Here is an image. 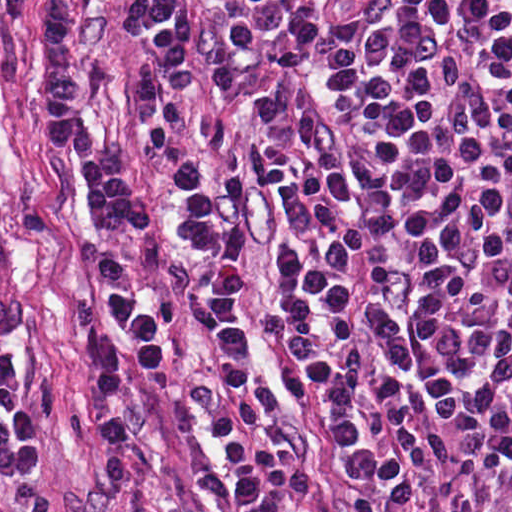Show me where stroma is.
<instances>
[{"label": "stroma", "instance_id": "obj_1", "mask_svg": "<svg viewBox=\"0 0 512 512\" xmlns=\"http://www.w3.org/2000/svg\"><path fill=\"white\" fill-rule=\"evenodd\" d=\"M69 1L85 44V127L127 161L158 210V229L144 234L124 220L91 233L68 156L35 124L40 0H0V394L39 435L26 473L0 478V512H235L209 390L206 325L189 291L193 260L173 234L172 190L138 133L134 64L164 80L193 141L242 177V123L266 76L249 43L253 20L227 0H195L200 89L180 99L136 28L119 22L123 0ZM284 245L278 217L252 198L243 274L256 358L277 387L283 427L314 471L310 499L291 512H397L331 445L326 393L261 319ZM113 286L165 329L161 360L140 362L125 351L128 454L101 448L92 428L87 335L107 327L99 300Z\"/></svg>", "mask_w": 512, "mask_h": 512}]
</instances>
